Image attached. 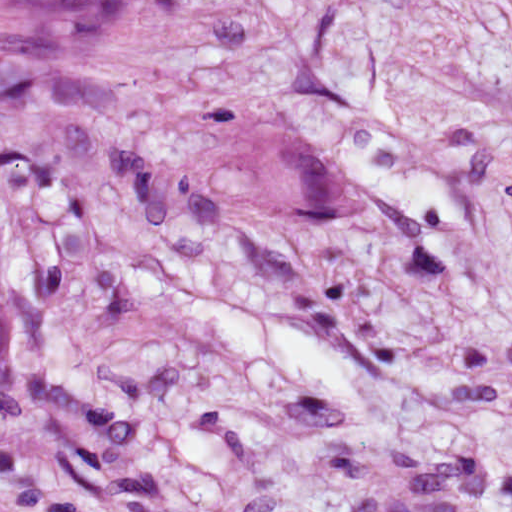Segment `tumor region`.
I'll list each match as a JSON object with an SVG mask.
<instances>
[{
  "label": "tumor region",
  "mask_w": 512,
  "mask_h": 512,
  "mask_svg": "<svg viewBox=\"0 0 512 512\" xmlns=\"http://www.w3.org/2000/svg\"><path fill=\"white\" fill-rule=\"evenodd\" d=\"M149 0H0V15L64 41H111L129 32ZM319 142L261 145L249 162L247 197L265 212H314L327 197Z\"/></svg>",
  "instance_id": "e687c5a6"
}]
</instances>
